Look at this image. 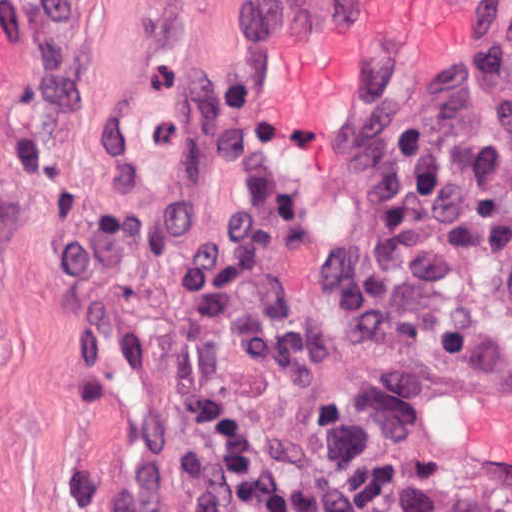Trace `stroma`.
I'll return each instance as SVG.
<instances>
[{
	"instance_id": "35a3bbf8",
	"label": "stroma",
	"mask_w": 512,
	"mask_h": 512,
	"mask_svg": "<svg viewBox=\"0 0 512 512\" xmlns=\"http://www.w3.org/2000/svg\"><path fill=\"white\" fill-rule=\"evenodd\" d=\"M250 1L0 0V512H246L214 485L188 415L170 263L230 202L201 106L248 71ZM264 109L304 213L275 254L324 347L316 394L295 401L219 345L265 450L294 485H344L352 512H512V495L432 461L419 428V400L512 362L500 272L472 262L444 286L470 321L463 357L343 342L319 267L366 176L296 168Z\"/></svg>"
}]
</instances>
